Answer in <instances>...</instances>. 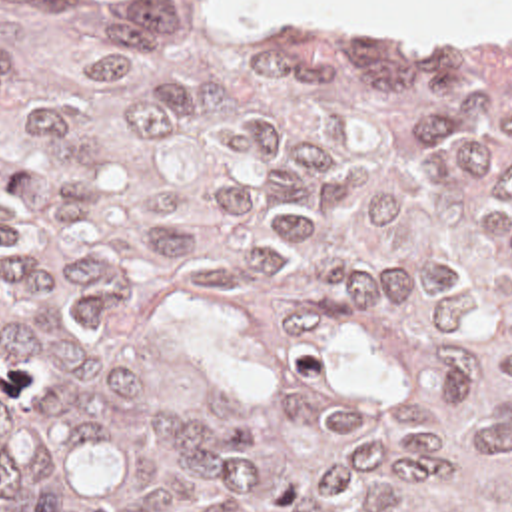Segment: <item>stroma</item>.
<instances>
[{"instance_id": "35a3bbf8", "label": "stroma", "mask_w": 512, "mask_h": 512, "mask_svg": "<svg viewBox=\"0 0 512 512\" xmlns=\"http://www.w3.org/2000/svg\"><path fill=\"white\" fill-rule=\"evenodd\" d=\"M243 4H255V6H289L281 2H267V0H237ZM303 14L305 18L318 24L320 28L330 31V33H348V35H370V37H380V39H390V41H402V43H512V35H450V33H436L428 29H418V31H406V33H372L366 29L350 28L342 26L334 20H328L318 14L303 12L295 6H289Z\"/></svg>"}]
</instances>
